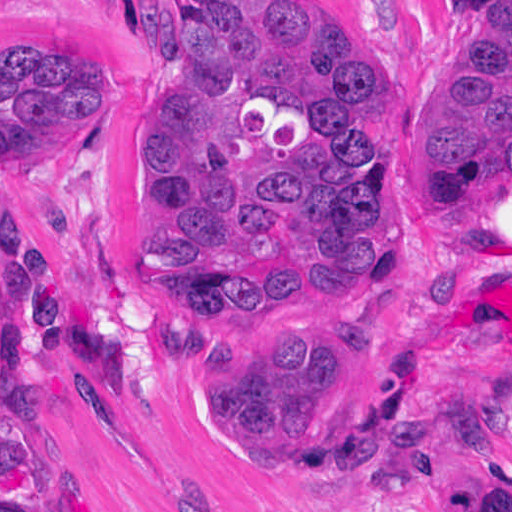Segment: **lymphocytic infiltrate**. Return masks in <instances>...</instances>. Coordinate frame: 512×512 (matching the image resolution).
<instances>
[{"label": "lymphocytic infiltrate", "instance_id": "1", "mask_svg": "<svg viewBox=\"0 0 512 512\" xmlns=\"http://www.w3.org/2000/svg\"><path fill=\"white\" fill-rule=\"evenodd\" d=\"M1 512H32L16 502L12 495L1 487Z\"/></svg>", "mask_w": 512, "mask_h": 512}]
</instances>
